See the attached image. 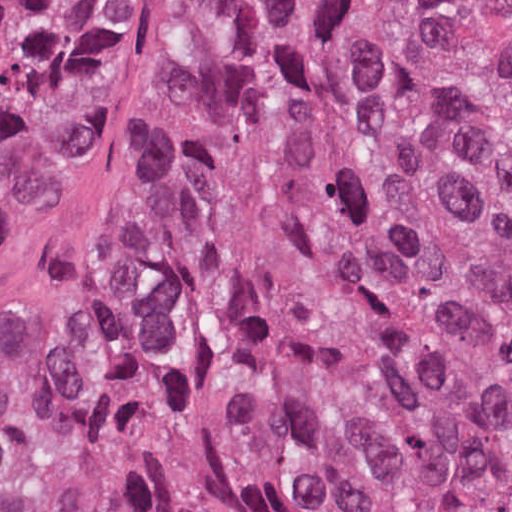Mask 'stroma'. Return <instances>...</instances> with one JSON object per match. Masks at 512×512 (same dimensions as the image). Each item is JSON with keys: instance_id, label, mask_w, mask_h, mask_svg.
<instances>
[{"instance_id": "stroma-1", "label": "stroma", "mask_w": 512, "mask_h": 512, "mask_svg": "<svg viewBox=\"0 0 512 512\" xmlns=\"http://www.w3.org/2000/svg\"><path fill=\"white\" fill-rule=\"evenodd\" d=\"M200 0H109L97 49L24 188L0 207V489L14 512H97L29 489L41 398L106 296Z\"/></svg>"}]
</instances>
